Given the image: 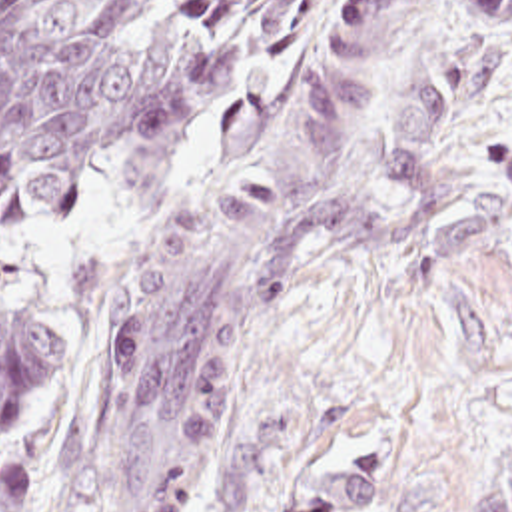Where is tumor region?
I'll return each instance as SVG.
<instances>
[{
  "mask_svg": "<svg viewBox=\"0 0 512 512\" xmlns=\"http://www.w3.org/2000/svg\"><path fill=\"white\" fill-rule=\"evenodd\" d=\"M323 0H0V230L57 228L103 176L165 190L213 122L265 84ZM414 0H351L333 50L251 160L141 244L83 324L77 475L171 431L219 427L233 386L303 284L398 250L416 230L370 222L333 194ZM474 48L408 62L382 158L426 202L448 124L512 26V0H466ZM71 340L0 296V439L29 427L67 378ZM31 479L0 471V512H33ZM201 475L165 455L127 512H183ZM382 463L341 459L299 487V512H369ZM51 512H71L67 509ZM470 512H512V447L476 469Z\"/></svg>",
  "mask_w": 512,
  "mask_h": 512,
  "instance_id": "obj_1",
  "label": "tumor region"
}]
</instances>
